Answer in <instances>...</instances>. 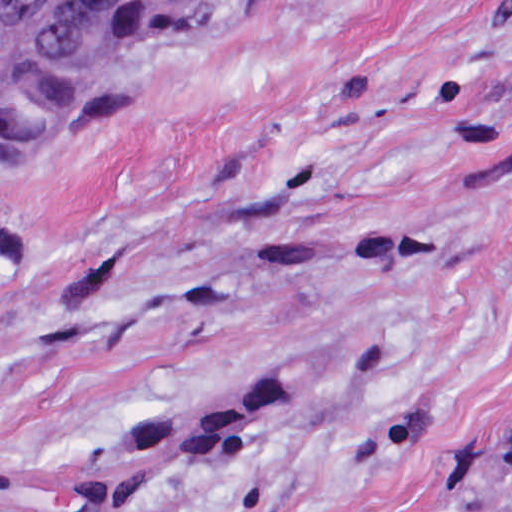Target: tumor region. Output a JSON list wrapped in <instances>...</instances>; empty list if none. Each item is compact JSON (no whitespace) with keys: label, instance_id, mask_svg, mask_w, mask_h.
Segmentation results:
<instances>
[{"label":"tumor region","instance_id":"e687c5a6","mask_svg":"<svg viewBox=\"0 0 512 512\" xmlns=\"http://www.w3.org/2000/svg\"><path fill=\"white\" fill-rule=\"evenodd\" d=\"M214 0H20L0 18V152L160 29ZM481 512H512V446Z\"/></svg>","mask_w":512,"mask_h":512}]
</instances>
